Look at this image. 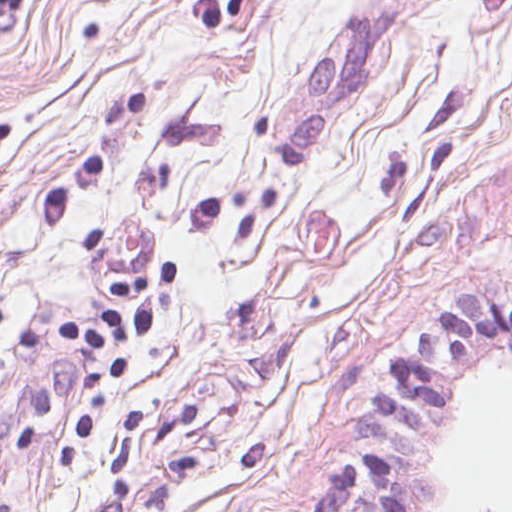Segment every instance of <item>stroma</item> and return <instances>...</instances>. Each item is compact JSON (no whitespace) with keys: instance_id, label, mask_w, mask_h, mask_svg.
<instances>
[{"instance_id":"35a3bbf8","label":"stroma","mask_w":512,"mask_h":512,"mask_svg":"<svg viewBox=\"0 0 512 512\" xmlns=\"http://www.w3.org/2000/svg\"><path fill=\"white\" fill-rule=\"evenodd\" d=\"M149 332L59 337L167 261ZM512 301V0H0V512H433L372 397ZM484 512H496L486 509Z\"/></svg>"}]
</instances>
